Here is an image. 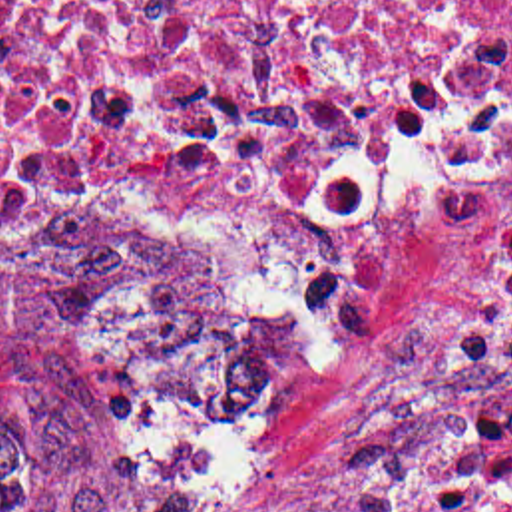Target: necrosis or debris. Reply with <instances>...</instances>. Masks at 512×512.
I'll return each instance as SVG.
<instances>
[{
	"label": "necrosis or debris",
	"instance_id": "obj_1",
	"mask_svg": "<svg viewBox=\"0 0 512 512\" xmlns=\"http://www.w3.org/2000/svg\"><path fill=\"white\" fill-rule=\"evenodd\" d=\"M512 203V0H0V243H230L328 352L408 223Z\"/></svg>",
	"mask_w": 512,
	"mask_h": 512
}]
</instances>
